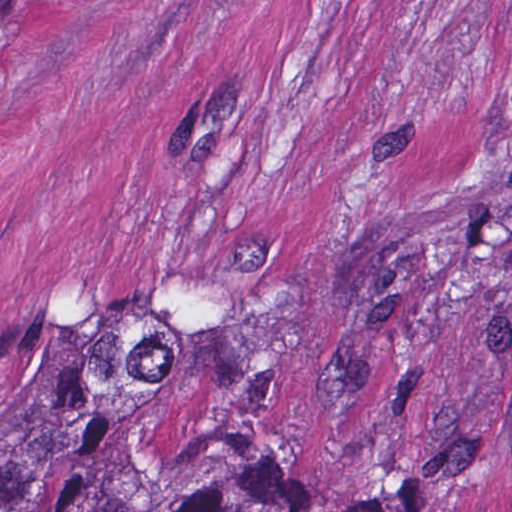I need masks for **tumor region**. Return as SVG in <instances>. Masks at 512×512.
Segmentation results:
<instances>
[{"label": "tumor region", "instance_id": "1", "mask_svg": "<svg viewBox=\"0 0 512 512\" xmlns=\"http://www.w3.org/2000/svg\"><path fill=\"white\" fill-rule=\"evenodd\" d=\"M34 0H0V23ZM0 512H298L270 458L246 449L200 454L131 483L70 441L0 437Z\"/></svg>", "mask_w": 512, "mask_h": 512}]
</instances>
